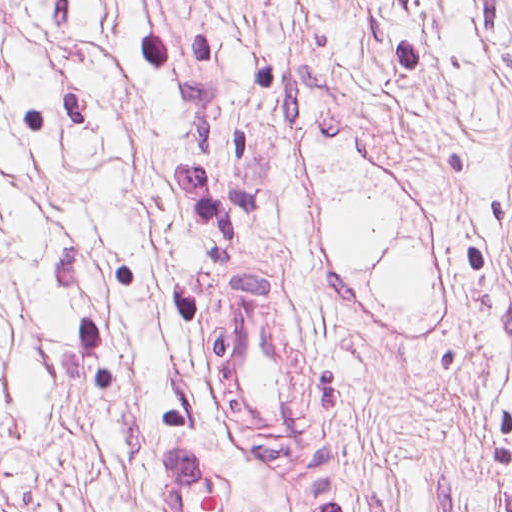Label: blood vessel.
Segmentation results:
<instances>
[{
    "mask_svg": "<svg viewBox=\"0 0 512 512\" xmlns=\"http://www.w3.org/2000/svg\"><path fill=\"white\" fill-rule=\"evenodd\" d=\"M219 264L213 279V353L268 459L317 460L331 407V349L258 266ZM201 443L149 437L146 470L170 512H239L227 466Z\"/></svg>",
    "mask_w": 512,
    "mask_h": 512,
    "instance_id": "1",
    "label": "blood vessel"
}]
</instances>
